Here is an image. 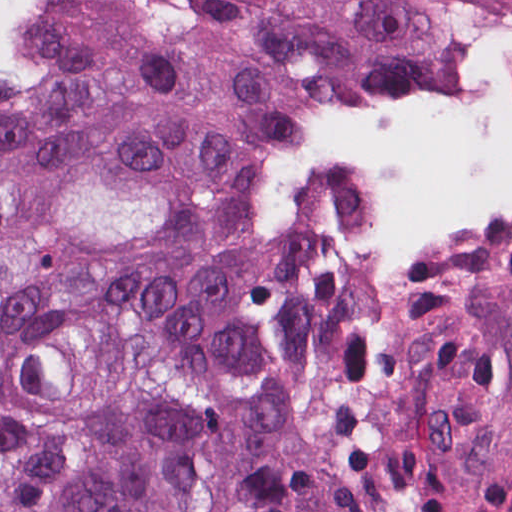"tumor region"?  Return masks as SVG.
<instances>
[{
	"label": "tumor region",
	"instance_id": "tumor-region-1",
	"mask_svg": "<svg viewBox=\"0 0 512 512\" xmlns=\"http://www.w3.org/2000/svg\"><path fill=\"white\" fill-rule=\"evenodd\" d=\"M25 7L0 43V512H512V259L288 251L223 53L358 248L512 249V0ZM59 27H88L98 33Z\"/></svg>",
	"mask_w": 512,
	"mask_h": 512
}]
</instances>
